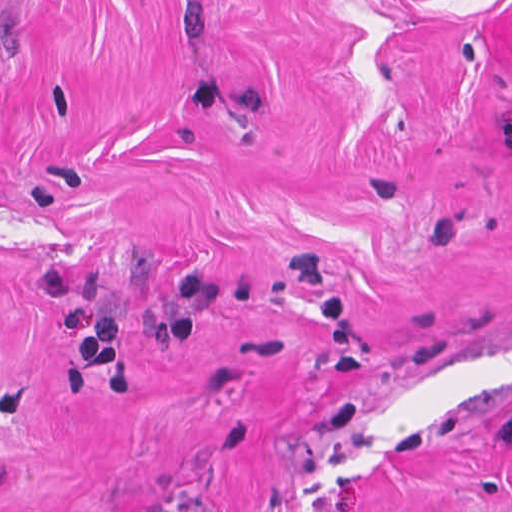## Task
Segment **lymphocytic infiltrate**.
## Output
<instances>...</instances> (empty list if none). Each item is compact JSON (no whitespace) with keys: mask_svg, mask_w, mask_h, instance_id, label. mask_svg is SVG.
Wrapping results in <instances>:
<instances>
[{"mask_svg":"<svg viewBox=\"0 0 512 512\" xmlns=\"http://www.w3.org/2000/svg\"><path fill=\"white\" fill-rule=\"evenodd\" d=\"M500 436L506 445L512 446V413L504 420L499 429Z\"/></svg>","mask_w":512,"mask_h":512,"instance_id":"1","label":"lymphocytic infiltrate"}]
</instances>
